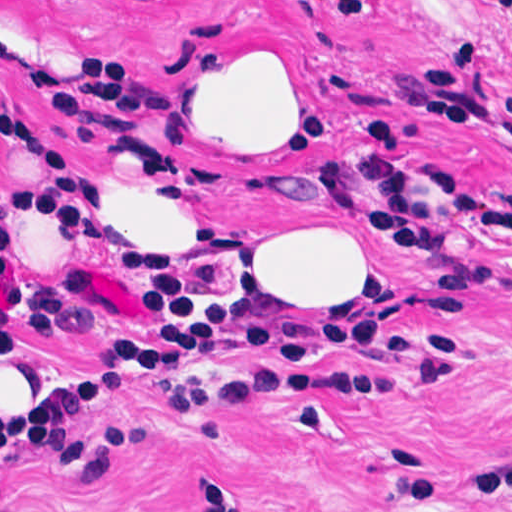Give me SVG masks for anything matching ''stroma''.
<instances>
[{
	"instance_id": "1",
	"label": "stroma",
	"mask_w": 512,
	"mask_h": 512,
	"mask_svg": "<svg viewBox=\"0 0 512 512\" xmlns=\"http://www.w3.org/2000/svg\"><path fill=\"white\" fill-rule=\"evenodd\" d=\"M285 46L316 70L326 149L289 189L243 183L182 137V106L227 51ZM0 119L54 134L99 172L130 246L128 203L175 166L208 179L234 295L391 334L478 345L477 371L433 388L408 364L344 348L288 359L222 342L201 381L252 368L340 371L269 381L233 406H170L141 372L78 415L156 443L117 452L95 496L49 457L0 446L2 512H512V0H0ZM45 173L0 135V177ZM346 221L391 264L372 287L301 303L279 282L282 234ZM0 237L15 260L0 307V410L121 380L127 346L185 299L108 228L38 210Z\"/></svg>"
}]
</instances>
